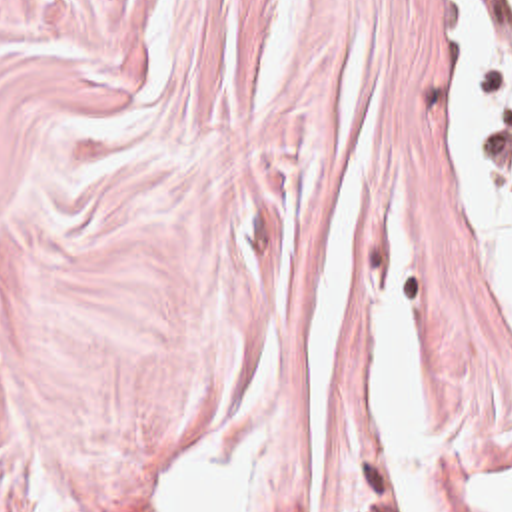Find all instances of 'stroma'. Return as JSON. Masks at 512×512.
<instances>
[{
    "mask_svg": "<svg viewBox=\"0 0 512 512\" xmlns=\"http://www.w3.org/2000/svg\"><path fill=\"white\" fill-rule=\"evenodd\" d=\"M446 6L0 0V512H156L158 474L300 354L368 160L434 412L512 442L510 314L452 224ZM282 512H400L350 332Z\"/></svg>",
    "mask_w": 512,
    "mask_h": 512,
    "instance_id": "obj_1",
    "label": "stroma"
}]
</instances>
